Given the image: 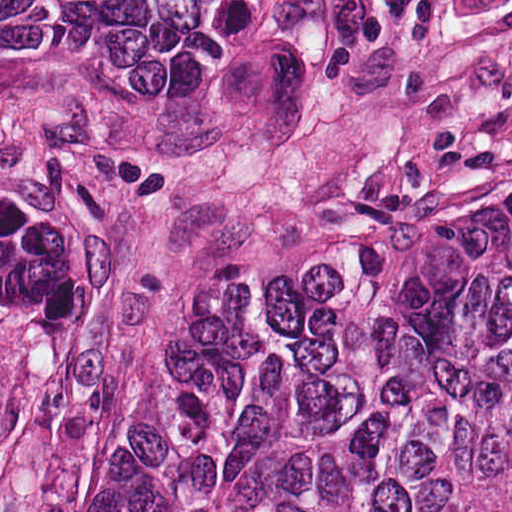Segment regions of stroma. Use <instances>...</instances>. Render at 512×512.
<instances>
[{"mask_svg":"<svg viewBox=\"0 0 512 512\" xmlns=\"http://www.w3.org/2000/svg\"><path fill=\"white\" fill-rule=\"evenodd\" d=\"M0 135L89 207V323L4 512H89L172 360L249 268L512 178V0H426L371 60L217 119L0 89Z\"/></svg>","mask_w":512,"mask_h":512,"instance_id":"stroma-1","label":"stroma"}]
</instances>
